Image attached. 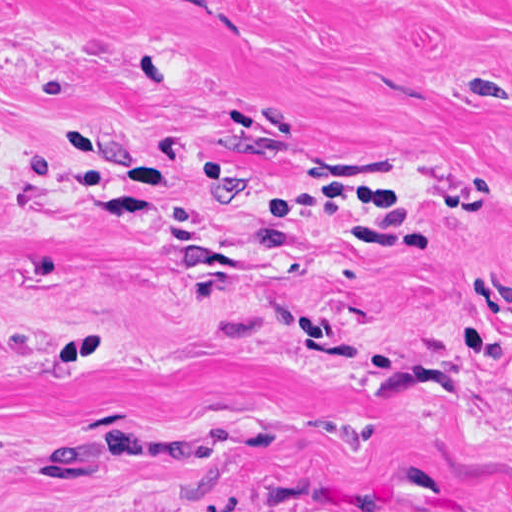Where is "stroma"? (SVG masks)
<instances>
[{
	"label": "stroma",
	"mask_w": 512,
	"mask_h": 512,
	"mask_svg": "<svg viewBox=\"0 0 512 512\" xmlns=\"http://www.w3.org/2000/svg\"><path fill=\"white\" fill-rule=\"evenodd\" d=\"M0 512H512V0H0Z\"/></svg>",
	"instance_id": "obj_1"
}]
</instances>
